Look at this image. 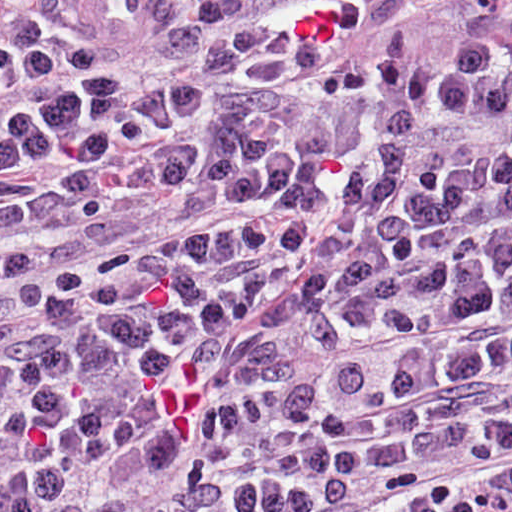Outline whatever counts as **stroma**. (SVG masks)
<instances>
[{
  "label": "stroma",
  "instance_id": "35a3bbf8",
  "mask_svg": "<svg viewBox=\"0 0 512 512\" xmlns=\"http://www.w3.org/2000/svg\"><path fill=\"white\" fill-rule=\"evenodd\" d=\"M66 0H0L1 5L31 6L42 3H62ZM426 2H458L512 9V0H421Z\"/></svg>",
  "mask_w": 512,
  "mask_h": 512
}]
</instances>
